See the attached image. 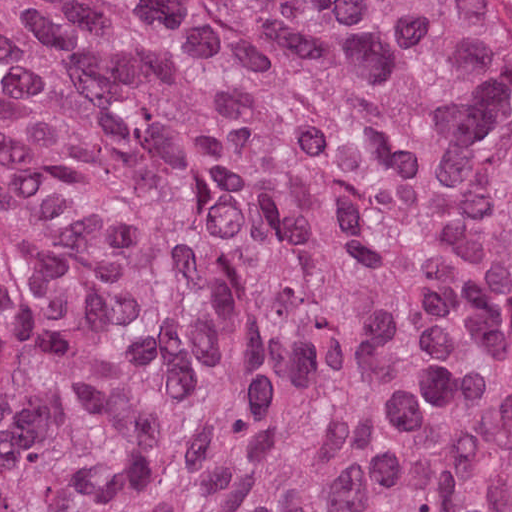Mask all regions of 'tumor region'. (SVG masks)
I'll return each mask as SVG.
<instances>
[{
    "instance_id": "tumor-region-1",
    "label": "tumor region",
    "mask_w": 512,
    "mask_h": 512,
    "mask_svg": "<svg viewBox=\"0 0 512 512\" xmlns=\"http://www.w3.org/2000/svg\"><path fill=\"white\" fill-rule=\"evenodd\" d=\"M0 512H512L500 0H0Z\"/></svg>"
}]
</instances>
